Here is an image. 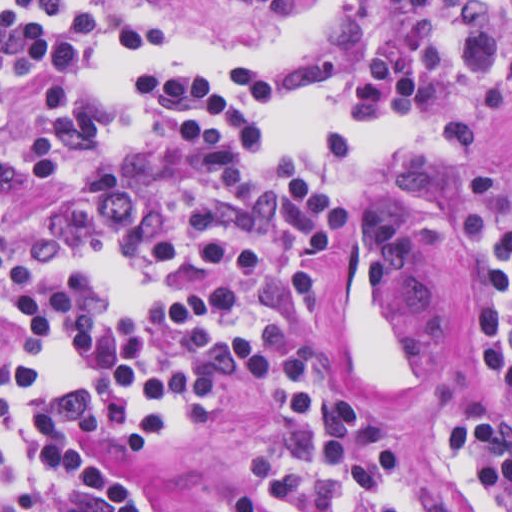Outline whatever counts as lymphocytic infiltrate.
Instances as JSON below:
<instances>
[{
    "instance_id": "1",
    "label": "lymphocytic infiltrate",
    "mask_w": 512,
    "mask_h": 512,
    "mask_svg": "<svg viewBox=\"0 0 512 512\" xmlns=\"http://www.w3.org/2000/svg\"><path fill=\"white\" fill-rule=\"evenodd\" d=\"M185 1H0L6 87L46 71L28 170L60 194L5 225L0 161V512H169L115 450L174 455L245 405L276 333L321 291L317 253L363 178L500 108L512 1H236L297 23L270 52L159 19ZM416 209L462 277L482 365L512 404V186L420 161ZM401 205L358 229L346 343L391 419L329 367L285 357L281 423L231 512H460L411 460L430 421L473 512H512V427L484 405H399Z\"/></svg>"
}]
</instances>
